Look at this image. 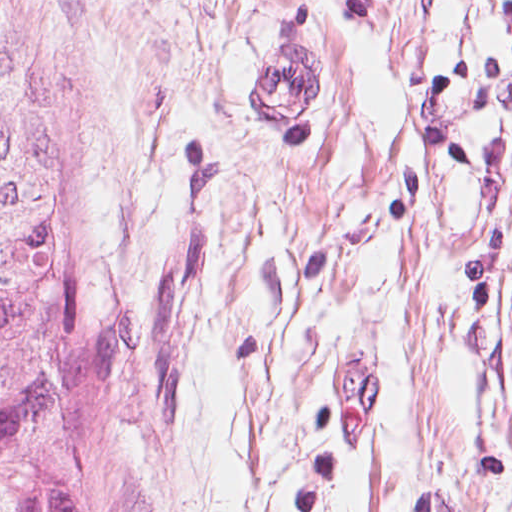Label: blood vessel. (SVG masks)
<instances>
[{
  "label": "blood vessel",
  "instance_id": "8fb6f2fc",
  "mask_svg": "<svg viewBox=\"0 0 512 512\" xmlns=\"http://www.w3.org/2000/svg\"><path fill=\"white\" fill-rule=\"evenodd\" d=\"M260 111L280 125H303L322 109V72L305 54L268 60L251 81ZM381 405V378L354 356L339 369V429L352 447H363Z\"/></svg>",
  "mask_w": 512,
  "mask_h": 512
}]
</instances>
